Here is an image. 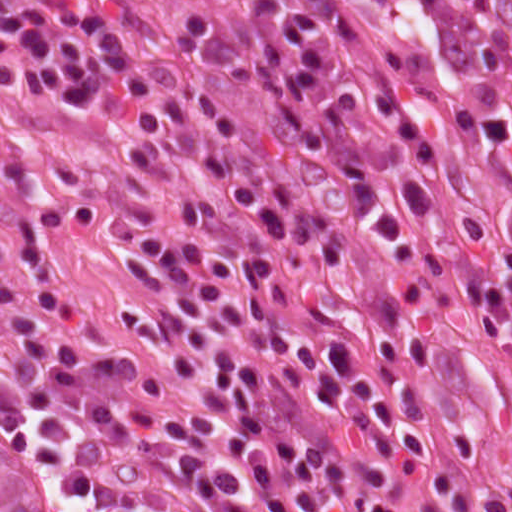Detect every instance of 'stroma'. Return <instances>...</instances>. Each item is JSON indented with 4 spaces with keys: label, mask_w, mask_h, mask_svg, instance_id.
I'll use <instances>...</instances> for the list:
<instances>
[{
    "label": "stroma",
    "mask_w": 512,
    "mask_h": 512,
    "mask_svg": "<svg viewBox=\"0 0 512 512\" xmlns=\"http://www.w3.org/2000/svg\"><path fill=\"white\" fill-rule=\"evenodd\" d=\"M178 22H199L201 0H118ZM309 24L327 93L347 155L370 213H390L411 161L372 107L389 95ZM395 97V96H394ZM156 140L115 115L53 112L28 93L0 85V278L23 290L79 289L104 331L125 329L111 248L83 230L64 237L55 195L131 178ZM441 206L414 214L424 238L421 256L393 266L414 312L461 397L478 439L498 512H512L503 495L512 484V334H485L469 285L497 282L505 255L475 219L457 169L444 162L430 177ZM0 512H65L50 479L0 415Z\"/></svg>",
    "instance_id": "stroma-1"
}]
</instances>
